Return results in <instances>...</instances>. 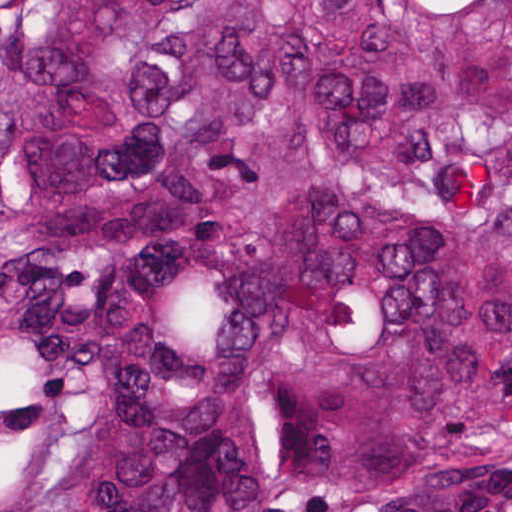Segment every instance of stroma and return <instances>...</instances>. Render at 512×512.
<instances>
[{
    "label": "stroma",
    "instance_id": "35a3bbf8",
    "mask_svg": "<svg viewBox=\"0 0 512 512\" xmlns=\"http://www.w3.org/2000/svg\"><path fill=\"white\" fill-rule=\"evenodd\" d=\"M336 512H512V426L499 431L477 475L368 500Z\"/></svg>",
    "mask_w": 512,
    "mask_h": 512
}]
</instances>
